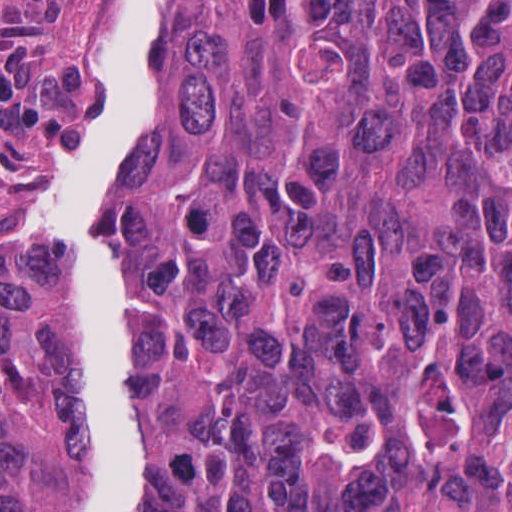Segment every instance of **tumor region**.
<instances>
[{
	"label": "tumor region",
	"mask_w": 512,
	"mask_h": 512,
	"mask_svg": "<svg viewBox=\"0 0 512 512\" xmlns=\"http://www.w3.org/2000/svg\"><path fill=\"white\" fill-rule=\"evenodd\" d=\"M42 228L0 279V496L58 348ZM123 512H512V1H165Z\"/></svg>",
	"instance_id": "tumor-region-1"
}]
</instances>
